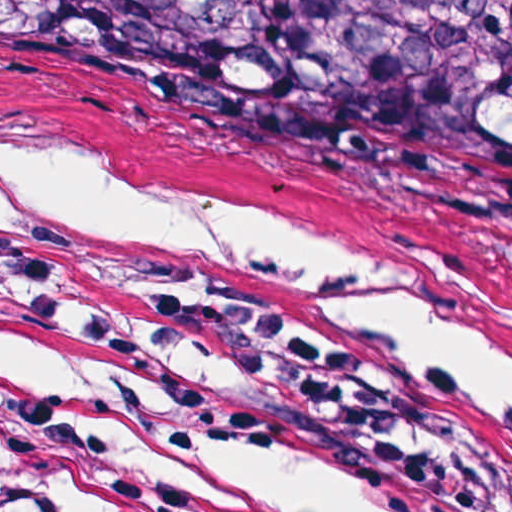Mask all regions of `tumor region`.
<instances>
[{"mask_svg": "<svg viewBox=\"0 0 512 512\" xmlns=\"http://www.w3.org/2000/svg\"><path fill=\"white\" fill-rule=\"evenodd\" d=\"M0 94L512 196V0H0Z\"/></svg>", "mask_w": 512, "mask_h": 512, "instance_id": "e687c5a6", "label": "tumor region"}]
</instances>
